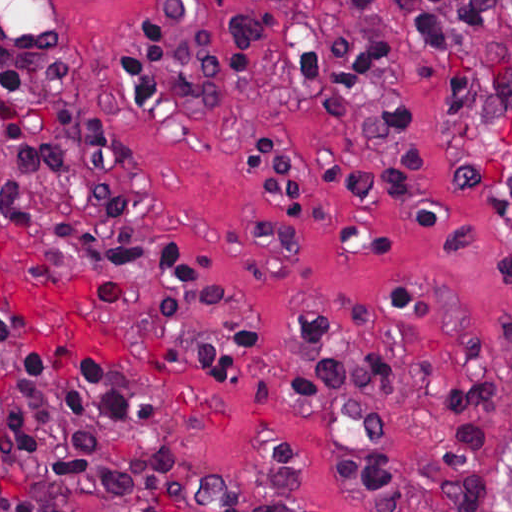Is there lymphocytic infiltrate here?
Wrapping results in <instances>:
<instances>
[{
    "label": "lymphocytic infiltrate",
    "instance_id": "f902f5d3",
    "mask_svg": "<svg viewBox=\"0 0 512 512\" xmlns=\"http://www.w3.org/2000/svg\"><path fill=\"white\" fill-rule=\"evenodd\" d=\"M416 72L453 122L512 72V1H139L116 67L123 101L162 132L232 97L234 144L281 199L311 196L270 93L335 99L333 170L363 188L418 173ZM0 167L8 224L34 271L93 313L146 372L234 401L250 378L238 315L178 241L122 133L93 104L42 1H0ZM229 389L137 353L83 301ZM293 387L327 400L345 477L369 512H412L377 423V345L293 320ZM170 423L148 395L29 318L0 311V496L11 512H169Z\"/></svg>",
    "mask_w": 512,
    "mask_h": 512
}]
</instances>
